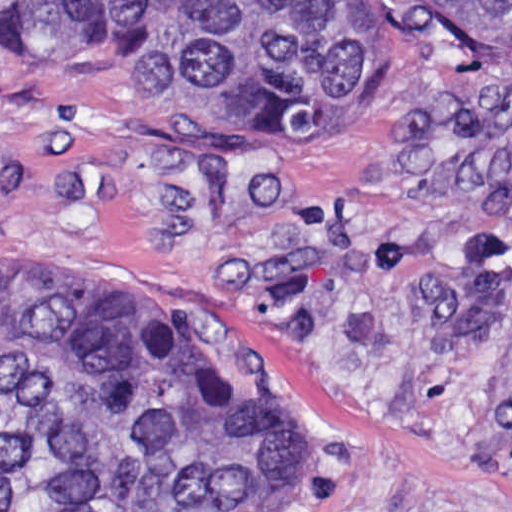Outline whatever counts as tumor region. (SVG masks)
<instances>
[{
	"instance_id": "tumor-region-1",
	"label": "tumor region",
	"mask_w": 512,
	"mask_h": 512,
	"mask_svg": "<svg viewBox=\"0 0 512 512\" xmlns=\"http://www.w3.org/2000/svg\"><path fill=\"white\" fill-rule=\"evenodd\" d=\"M436 48L512 63V0H0V70L147 117L295 105L362 128ZM324 431L241 400L213 311L0 244V512H318Z\"/></svg>"
}]
</instances>
